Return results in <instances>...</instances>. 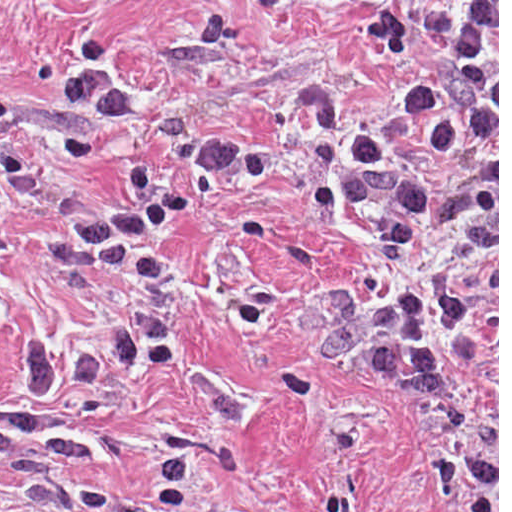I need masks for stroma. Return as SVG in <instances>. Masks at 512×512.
<instances>
[{
  "mask_svg": "<svg viewBox=\"0 0 512 512\" xmlns=\"http://www.w3.org/2000/svg\"><path fill=\"white\" fill-rule=\"evenodd\" d=\"M444 1H497V386L484 280L444 273L471 309L429 325L455 391L419 387L383 337V298L433 280L460 221L409 232L385 267L397 191L342 208L302 91L342 96L347 138L396 145L424 192L458 197L482 169L470 118L436 151L407 93L432 69ZM104 70L132 113L114 126L60 105L71 74ZM130 163L185 203L146 252L160 285L54 256L82 209L121 201ZM0 410L90 434L99 454L27 458L53 487L151 495L184 459L176 512H499V0H0ZM145 314L162 357L101 389L20 387L21 339L99 345ZM0 512H48L0 463Z\"/></svg>",
  "mask_w": 512,
  "mask_h": 512,
  "instance_id": "obj_1",
  "label": "stroma"
}]
</instances>
